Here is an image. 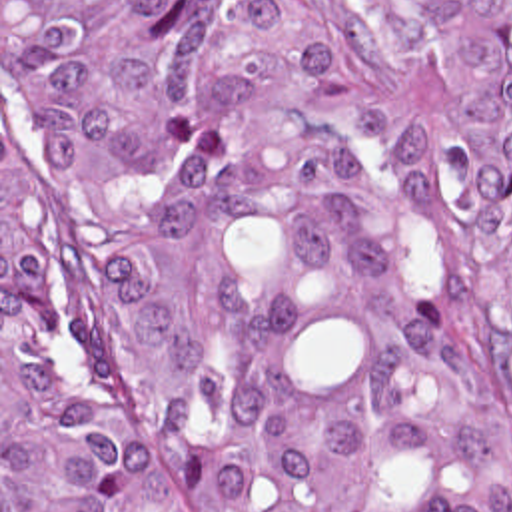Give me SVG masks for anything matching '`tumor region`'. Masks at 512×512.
Segmentation results:
<instances>
[{
	"label": "tumor region",
	"mask_w": 512,
	"mask_h": 512,
	"mask_svg": "<svg viewBox=\"0 0 512 512\" xmlns=\"http://www.w3.org/2000/svg\"><path fill=\"white\" fill-rule=\"evenodd\" d=\"M351 3L2 0V512H512L377 113L512 396V0Z\"/></svg>",
	"instance_id": "e687c5a6"
}]
</instances>
